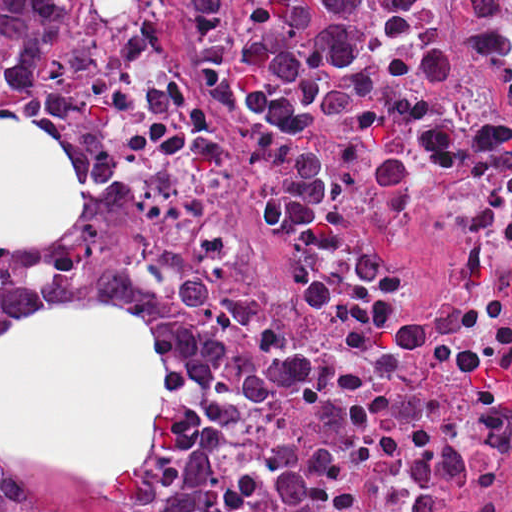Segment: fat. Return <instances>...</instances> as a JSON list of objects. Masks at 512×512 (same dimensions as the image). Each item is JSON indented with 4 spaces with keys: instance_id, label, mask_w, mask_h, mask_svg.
<instances>
[{
    "instance_id": "1",
    "label": "fat",
    "mask_w": 512,
    "mask_h": 512,
    "mask_svg": "<svg viewBox=\"0 0 512 512\" xmlns=\"http://www.w3.org/2000/svg\"><path fill=\"white\" fill-rule=\"evenodd\" d=\"M88 186L48 125L0 114V250H48ZM164 414V341L132 305L53 294L0 336V460L137 475Z\"/></svg>"
}]
</instances>
